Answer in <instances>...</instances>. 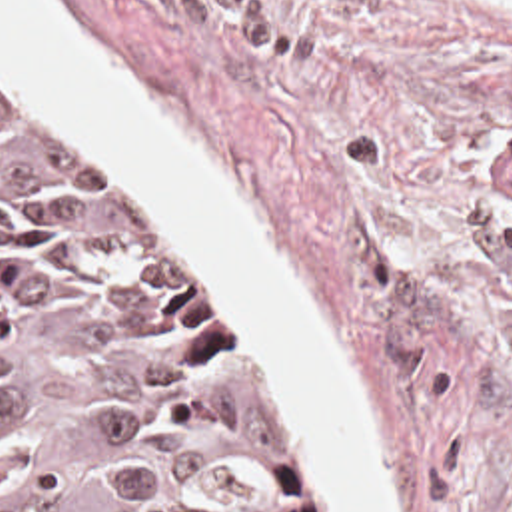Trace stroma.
Masks as SVG:
<instances>
[{"label":"stroma","mask_w":512,"mask_h":512,"mask_svg":"<svg viewBox=\"0 0 512 512\" xmlns=\"http://www.w3.org/2000/svg\"><path fill=\"white\" fill-rule=\"evenodd\" d=\"M183 122L297 262L351 364L401 512H512V0H57ZM179 230L263 332L343 512L303 383L227 264Z\"/></svg>","instance_id":"35a3bbf8"}]
</instances>
